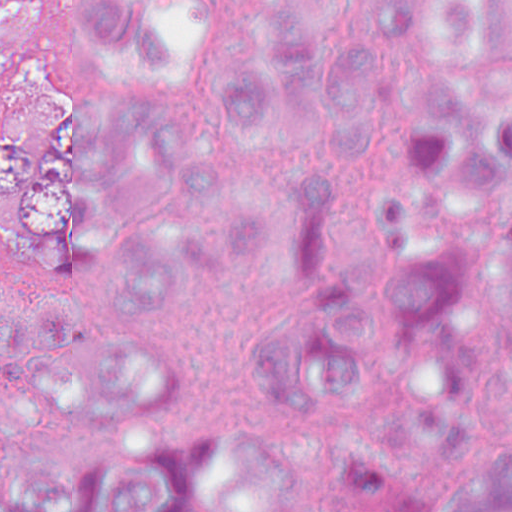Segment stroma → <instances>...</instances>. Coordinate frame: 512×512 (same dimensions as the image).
I'll return each mask as SVG.
<instances>
[{"label": "stroma", "instance_id": "1", "mask_svg": "<svg viewBox=\"0 0 512 512\" xmlns=\"http://www.w3.org/2000/svg\"><path fill=\"white\" fill-rule=\"evenodd\" d=\"M32 1L0 0V93L27 62V20Z\"/></svg>", "mask_w": 512, "mask_h": 512}]
</instances>
